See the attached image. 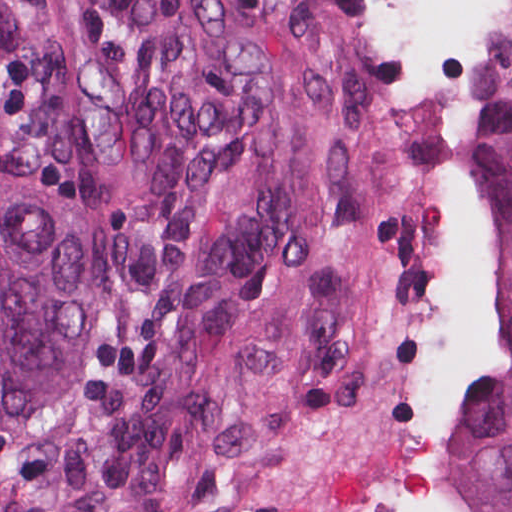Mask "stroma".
Instances as JSON below:
<instances>
[{"instance_id":"stroma-1","label":"stroma","mask_w":512,"mask_h":512,"mask_svg":"<svg viewBox=\"0 0 512 512\" xmlns=\"http://www.w3.org/2000/svg\"><path fill=\"white\" fill-rule=\"evenodd\" d=\"M231 44L275 195L210 512H444L499 368L469 155L512 0H117Z\"/></svg>"}]
</instances>
